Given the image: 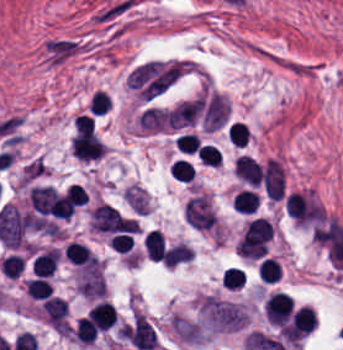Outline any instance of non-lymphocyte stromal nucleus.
I'll return each mask as SVG.
<instances>
[{"label": "non-lymphocyte stromal nucleus", "mask_w": 343, "mask_h": 350, "mask_svg": "<svg viewBox=\"0 0 343 350\" xmlns=\"http://www.w3.org/2000/svg\"><path fill=\"white\" fill-rule=\"evenodd\" d=\"M204 325L214 331L241 329L248 321V313L242 305L212 294H205L198 304Z\"/></svg>", "instance_id": "1"}, {"label": "non-lymphocyte stromal nucleus", "mask_w": 343, "mask_h": 350, "mask_svg": "<svg viewBox=\"0 0 343 350\" xmlns=\"http://www.w3.org/2000/svg\"><path fill=\"white\" fill-rule=\"evenodd\" d=\"M75 284L78 292L87 299L104 297V276L99 262L82 267L77 274Z\"/></svg>", "instance_id": "2"}, {"label": "non-lymphocyte stromal nucleus", "mask_w": 343, "mask_h": 350, "mask_svg": "<svg viewBox=\"0 0 343 350\" xmlns=\"http://www.w3.org/2000/svg\"><path fill=\"white\" fill-rule=\"evenodd\" d=\"M231 106L225 94L213 92L203 112V126L205 131H213L224 125Z\"/></svg>", "instance_id": "4"}, {"label": "non-lymphocyte stromal nucleus", "mask_w": 343, "mask_h": 350, "mask_svg": "<svg viewBox=\"0 0 343 350\" xmlns=\"http://www.w3.org/2000/svg\"><path fill=\"white\" fill-rule=\"evenodd\" d=\"M261 182L263 192L270 200L281 197L284 189V168L274 157H267L261 170Z\"/></svg>", "instance_id": "3"}]
</instances>
